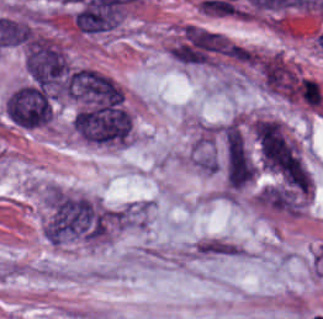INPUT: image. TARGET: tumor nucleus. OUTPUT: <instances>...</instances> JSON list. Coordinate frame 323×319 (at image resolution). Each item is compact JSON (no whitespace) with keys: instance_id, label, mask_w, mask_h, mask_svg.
<instances>
[{"instance_id":"obj_2","label":"tumor nucleus","mask_w":323,"mask_h":319,"mask_svg":"<svg viewBox=\"0 0 323 319\" xmlns=\"http://www.w3.org/2000/svg\"><path fill=\"white\" fill-rule=\"evenodd\" d=\"M4 113L7 119L22 128L46 125L53 115V103L44 88L36 83L22 82L6 97Z\"/></svg>"},{"instance_id":"obj_1","label":"tumor nucleus","mask_w":323,"mask_h":319,"mask_svg":"<svg viewBox=\"0 0 323 319\" xmlns=\"http://www.w3.org/2000/svg\"><path fill=\"white\" fill-rule=\"evenodd\" d=\"M256 134L262 164L290 183L307 186L299 151L279 121L258 120Z\"/></svg>"},{"instance_id":"obj_3","label":"tumor nucleus","mask_w":323,"mask_h":319,"mask_svg":"<svg viewBox=\"0 0 323 319\" xmlns=\"http://www.w3.org/2000/svg\"><path fill=\"white\" fill-rule=\"evenodd\" d=\"M222 171L227 187L252 182L253 157L241 121L231 120L221 129Z\"/></svg>"}]
</instances>
